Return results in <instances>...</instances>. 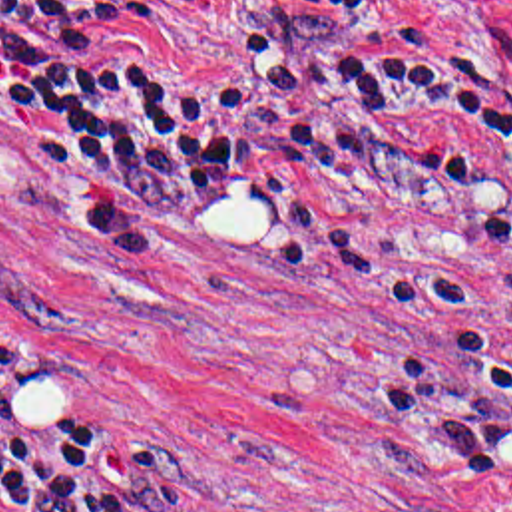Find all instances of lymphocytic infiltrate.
<instances>
[{
  "label": "lymphocytic infiltrate",
  "instance_id": "f902f5d3",
  "mask_svg": "<svg viewBox=\"0 0 512 512\" xmlns=\"http://www.w3.org/2000/svg\"><path fill=\"white\" fill-rule=\"evenodd\" d=\"M300 15H370L382 0H272ZM161 0H0V91L37 146L137 234H200L278 204L342 162L412 166L388 112L449 103L512 146V111L463 101L410 71L404 29L316 51L244 33L220 79L143 51ZM0 491L13 512H177L181 475L121 427L45 419L11 427L0 346Z\"/></svg>",
  "mask_w": 512,
  "mask_h": 512
}]
</instances>
